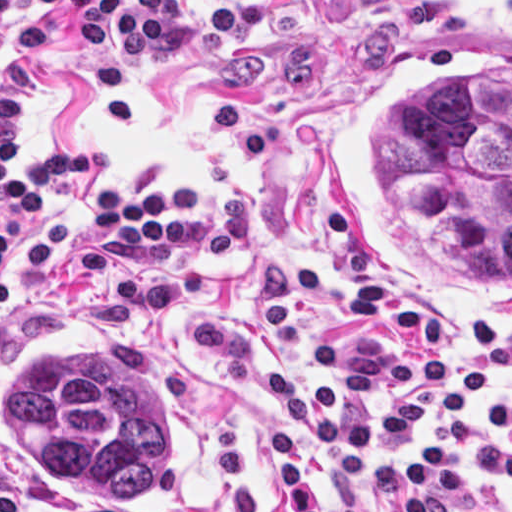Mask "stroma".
<instances>
[{
	"mask_svg": "<svg viewBox=\"0 0 512 512\" xmlns=\"http://www.w3.org/2000/svg\"><path fill=\"white\" fill-rule=\"evenodd\" d=\"M187 14L160 47L130 56L82 47L55 12L39 53L0 70L26 93L8 153L28 174L41 149L111 145L109 170L35 198L76 221L73 249L47 271H13L0 314V450L18 483L16 512H296L280 482L278 425L300 434L313 492L342 512L315 434L234 386L190 332L241 341L257 368L303 388L341 382L312 364L319 343L355 353L460 354L486 389H512V324H428L375 299L348 271L325 207V169L350 91L404 36L368 0H183ZM140 200L159 189L184 215L173 240L116 242L96 221L108 191ZM104 352L142 370L162 421V485L138 502H111L57 480L3 414V390L52 346ZM479 393L462 419L444 418L448 391L399 387L345 410L374 412L397 395L421 397L428 422L405 444L369 445L404 470L416 447L441 444L467 497L512 512V486L472 460L465 424L486 420ZM511 434L509 432H503ZM365 512H392L362 491Z\"/></svg>",
	"mask_w": 512,
	"mask_h": 512,
	"instance_id": "stroma-1",
	"label": "stroma"
}]
</instances>
